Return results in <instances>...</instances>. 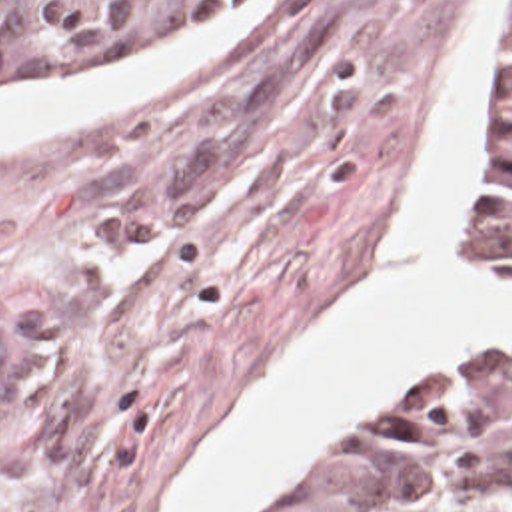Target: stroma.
I'll use <instances>...</instances> for the list:
<instances>
[{"label": "stroma", "mask_w": 512, "mask_h": 512, "mask_svg": "<svg viewBox=\"0 0 512 512\" xmlns=\"http://www.w3.org/2000/svg\"><path fill=\"white\" fill-rule=\"evenodd\" d=\"M463 17L465 0H283L189 81L0 143V512H171L247 395L387 271ZM510 35L499 0L459 217V263L501 281L481 209ZM485 345L512 339L455 353ZM451 355L317 434L251 512Z\"/></svg>", "instance_id": "35a3bbf8"}]
</instances>
